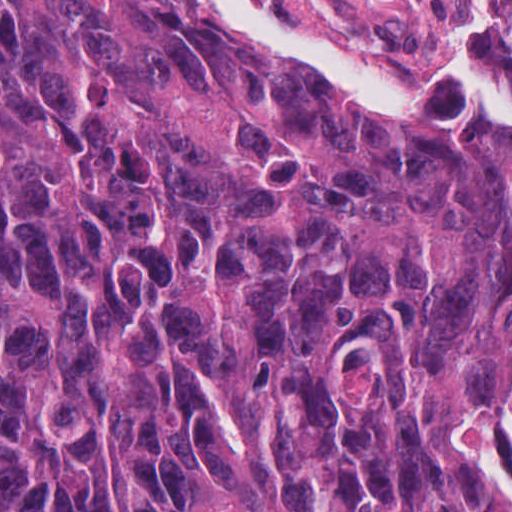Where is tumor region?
<instances>
[{
    "mask_svg": "<svg viewBox=\"0 0 512 512\" xmlns=\"http://www.w3.org/2000/svg\"><path fill=\"white\" fill-rule=\"evenodd\" d=\"M511 411V118L0 0V512H493Z\"/></svg>",
    "mask_w": 512,
    "mask_h": 512,
    "instance_id": "tumor-region-1",
    "label": "tumor region"
}]
</instances>
